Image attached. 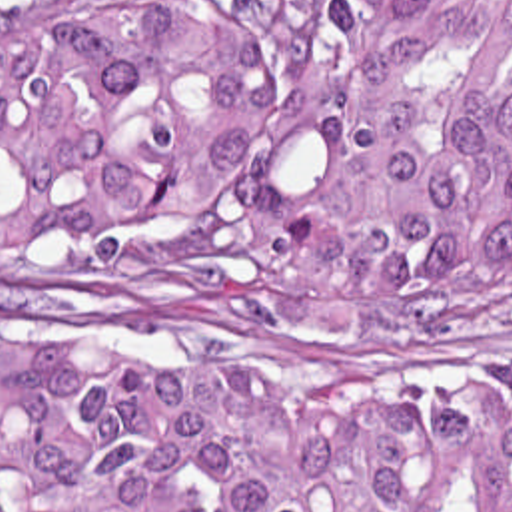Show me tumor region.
Instances as JSON below:
<instances>
[{
    "label": "tumor region",
    "instance_id": "e687c5a6",
    "mask_svg": "<svg viewBox=\"0 0 512 512\" xmlns=\"http://www.w3.org/2000/svg\"><path fill=\"white\" fill-rule=\"evenodd\" d=\"M0 253L145 307L465 339L512 289V0H0ZM0 512H512V394L241 390L0 345Z\"/></svg>",
    "mask_w": 512,
    "mask_h": 512
}]
</instances>
